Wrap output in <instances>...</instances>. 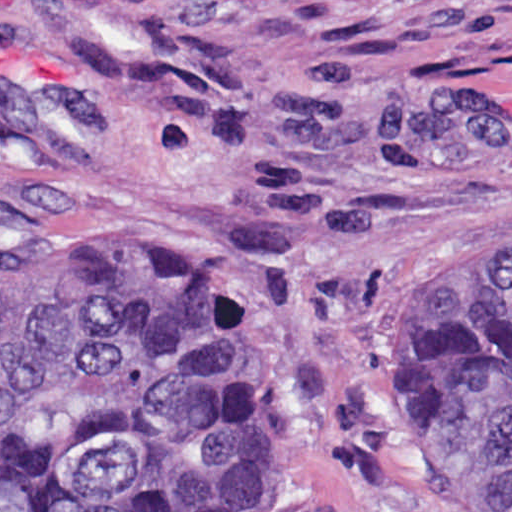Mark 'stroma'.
Here are the masks:
<instances>
[{
    "label": "stroma",
    "instance_id": "35a3bbf8",
    "mask_svg": "<svg viewBox=\"0 0 512 512\" xmlns=\"http://www.w3.org/2000/svg\"><path fill=\"white\" fill-rule=\"evenodd\" d=\"M512 208V0H0V246L172 268L279 383V466L208 512H446L429 356Z\"/></svg>",
    "mask_w": 512,
    "mask_h": 512
}]
</instances>
